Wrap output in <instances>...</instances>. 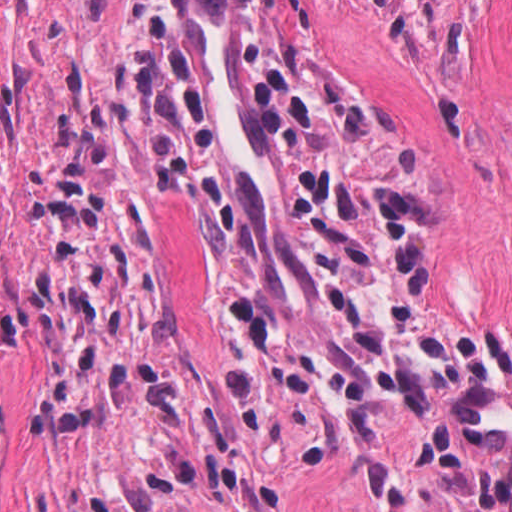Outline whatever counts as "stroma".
Wrapping results in <instances>:
<instances>
[{
	"instance_id": "obj_1",
	"label": "stroma",
	"mask_w": 512,
	"mask_h": 512,
	"mask_svg": "<svg viewBox=\"0 0 512 512\" xmlns=\"http://www.w3.org/2000/svg\"><path fill=\"white\" fill-rule=\"evenodd\" d=\"M0 512H440L144 0H0Z\"/></svg>"
}]
</instances>
